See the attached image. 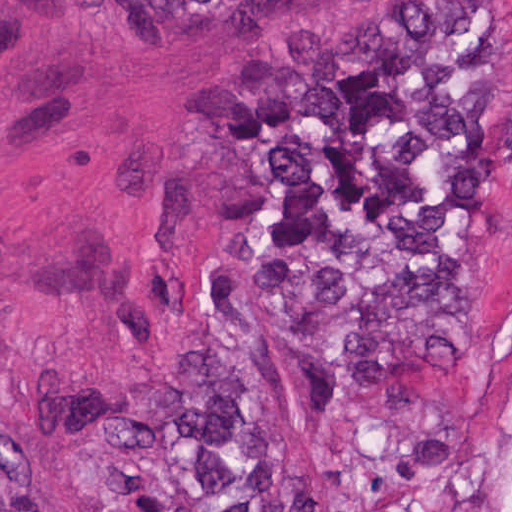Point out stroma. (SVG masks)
<instances>
[{"label":"stroma","instance_id":"stroma-1","mask_svg":"<svg viewBox=\"0 0 512 512\" xmlns=\"http://www.w3.org/2000/svg\"><path fill=\"white\" fill-rule=\"evenodd\" d=\"M414 1L276 0L242 28L152 0H0V390L52 512H91V460L38 437L25 403L181 343L257 55ZM492 1L512 32V0ZM476 380L475 449L512 454V122Z\"/></svg>","mask_w":512,"mask_h":512}]
</instances>
